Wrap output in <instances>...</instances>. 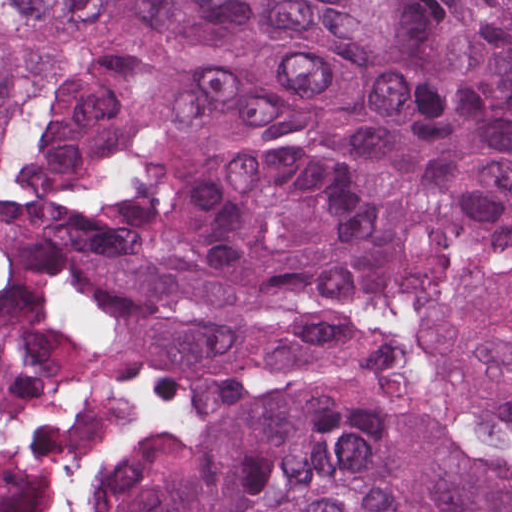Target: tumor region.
Returning a JSON list of instances; mask_svg holds the SVG:
<instances>
[{"mask_svg": "<svg viewBox=\"0 0 512 512\" xmlns=\"http://www.w3.org/2000/svg\"><path fill=\"white\" fill-rule=\"evenodd\" d=\"M0 512H512V0H0Z\"/></svg>", "mask_w": 512, "mask_h": 512, "instance_id": "e687c5a6", "label": "tumor region"}]
</instances>
